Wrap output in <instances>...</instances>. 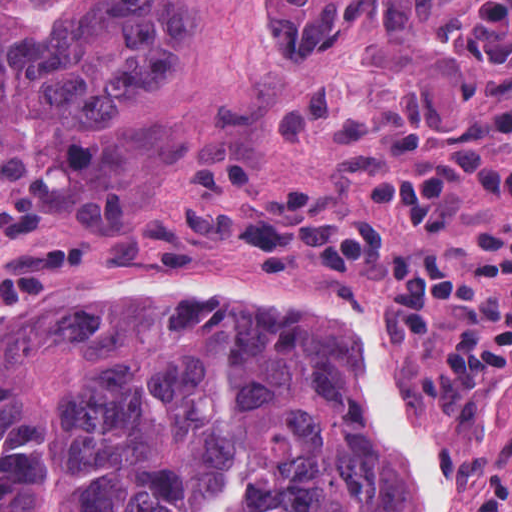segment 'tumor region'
<instances>
[{
	"mask_svg": "<svg viewBox=\"0 0 512 512\" xmlns=\"http://www.w3.org/2000/svg\"><path fill=\"white\" fill-rule=\"evenodd\" d=\"M371 0H261L271 48L350 44ZM457 0H382L398 30ZM205 0H0V237L148 191L204 145L98 110L179 61ZM92 262V261H91ZM345 332L230 339L106 304L32 311L0 341V512H437Z\"/></svg>",
	"mask_w": 512,
	"mask_h": 512,
	"instance_id": "1",
	"label": "tumor region"
}]
</instances>
